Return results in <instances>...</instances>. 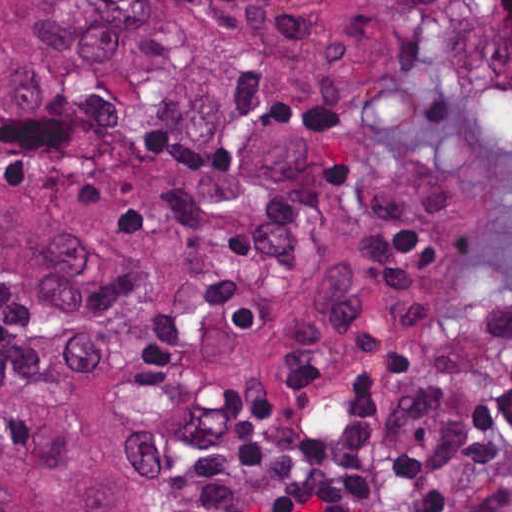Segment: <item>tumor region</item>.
Segmentation results:
<instances>
[{"label": "tumor region", "mask_w": 512, "mask_h": 512, "mask_svg": "<svg viewBox=\"0 0 512 512\" xmlns=\"http://www.w3.org/2000/svg\"><path fill=\"white\" fill-rule=\"evenodd\" d=\"M512 200V0H0V512H174L404 375Z\"/></svg>", "instance_id": "tumor-region-1"}]
</instances>
